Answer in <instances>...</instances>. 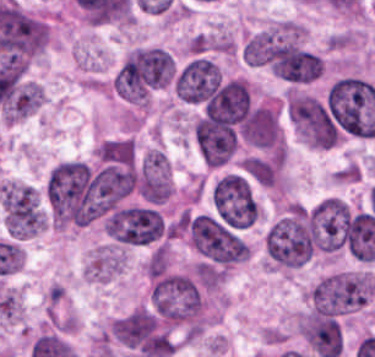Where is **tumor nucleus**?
<instances>
[{"mask_svg":"<svg viewBox=\"0 0 375 357\" xmlns=\"http://www.w3.org/2000/svg\"><path fill=\"white\" fill-rule=\"evenodd\" d=\"M105 229L120 244H151L164 233L160 214L148 207L128 206L115 209Z\"/></svg>","mask_w":375,"mask_h":357,"instance_id":"3","label":"tumor nucleus"},{"mask_svg":"<svg viewBox=\"0 0 375 357\" xmlns=\"http://www.w3.org/2000/svg\"><path fill=\"white\" fill-rule=\"evenodd\" d=\"M375 294V279L363 270L331 272L309 289L311 310L349 315L369 305Z\"/></svg>","mask_w":375,"mask_h":357,"instance_id":"1","label":"tumor nucleus"},{"mask_svg":"<svg viewBox=\"0 0 375 357\" xmlns=\"http://www.w3.org/2000/svg\"><path fill=\"white\" fill-rule=\"evenodd\" d=\"M241 53L249 66H268L273 53V31L261 30L247 37Z\"/></svg>","mask_w":375,"mask_h":357,"instance_id":"5","label":"tumor nucleus"},{"mask_svg":"<svg viewBox=\"0 0 375 357\" xmlns=\"http://www.w3.org/2000/svg\"><path fill=\"white\" fill-rule=\"evenodd\" d=\"M121 264V248L116 245H102L90 257L85 271L89 280L106 282L118 273Z\"/></svg>","mask_w":375,"mask_h":357,"instance_id":"4","label":"tumor nucleus"},{"mask_svg":"<svg viewBox=\"0 0 375 357\" xmlns=\"http://www.w3.org/2000/svg\"><path fill=\"white\" fill-rule=\"evenodd\" d=\"M187 230L192 245L199 252L222 263L230 265L250 255L248 242L210 214L187 219Z\"/></svg>","mask_w":375,"mask_h":357,"instance_id":"2","label":"tumor nucleus"}]
</instances>
